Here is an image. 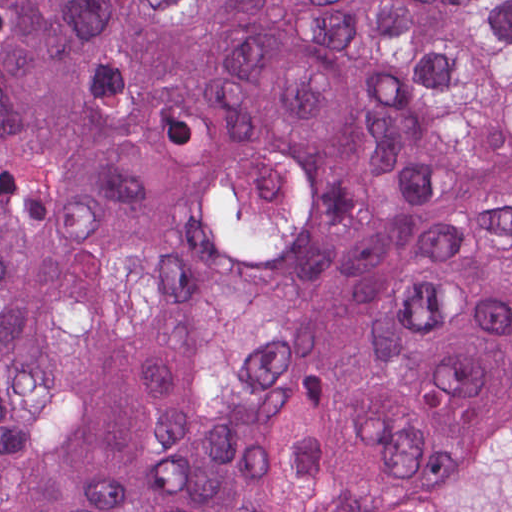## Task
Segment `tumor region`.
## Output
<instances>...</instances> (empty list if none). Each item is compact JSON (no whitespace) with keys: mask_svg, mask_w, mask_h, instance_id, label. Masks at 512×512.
Masks as SVG:
<instances>
[{"mask_svg":"<svg viewBox=\"0 0 512 512\" xmlns=\"http://www.w3.org/2000/svg\"><path fill=\"white\" fill-rule=\"evenodd\" d=\"M263 132L333 178L355 339L512 402V0H0V328L178 220ZM382 409L310 260L178 261L0 351V512H334L466 440Z\"/></svg>","mask_w":512,"mask_h":512,"instance_id":"1","label":"tumor region"}]
</instances>
